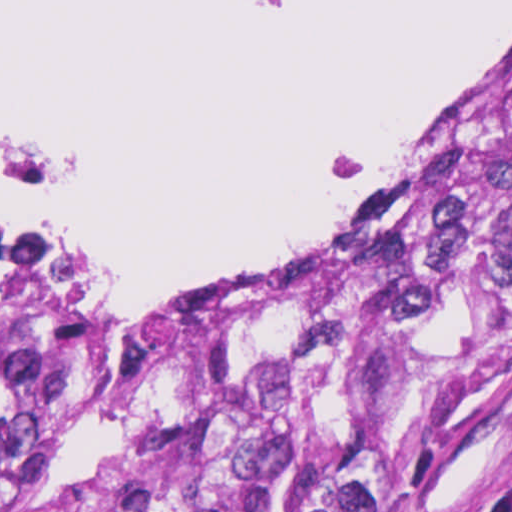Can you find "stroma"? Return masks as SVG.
<instances>
[{
    "label": "stroma",
    "mask_w": 512,
    "mask_h": 512,
    "mask_svg": "<svg viewBox=\"0 0 512 512\" xmlns=\"http://www.w3.org/2000/svg\"><path fill=\"white\" fill-rule=\"evenodd\" d=\"M511 46L512 31L468 71L362 222L307 257L228 290L281 280L315 287L312 277L352 246L444 113L484 83ZM202 294L208 293H149L101 306L76 290L69 305L28 317L26 348L139 308ZM416 417L433 427L436 512H463L507 498L512 484V342L470 373H416Z\"/></svg>",
    "instance_id": "35a3bbf8"
}]
</instances>
